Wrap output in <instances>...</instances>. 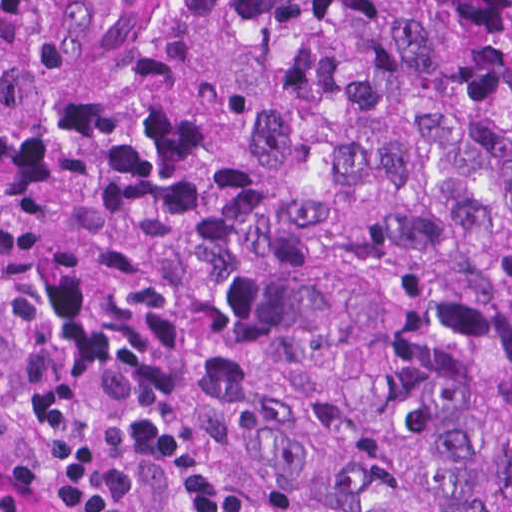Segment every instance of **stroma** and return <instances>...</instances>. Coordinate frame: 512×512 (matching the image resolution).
<instances>
[{"label":"stroma","mask_w":512,"mask_h":512,"mask_svg":"<svg viewBox=\"0 0 512 512\" xmlns=\"http://www.w3.org/2000/svg\"><path fill=\"white\" fill-rule=\"evenodd\" d=\"M0 374L7 392L52 440L120 455L124 467L174 512H247L231 476L192 466L167 433L113 417L73 392L2 321Z\"/></svg>","instance_id":"stroma-1"}]
</instances>
